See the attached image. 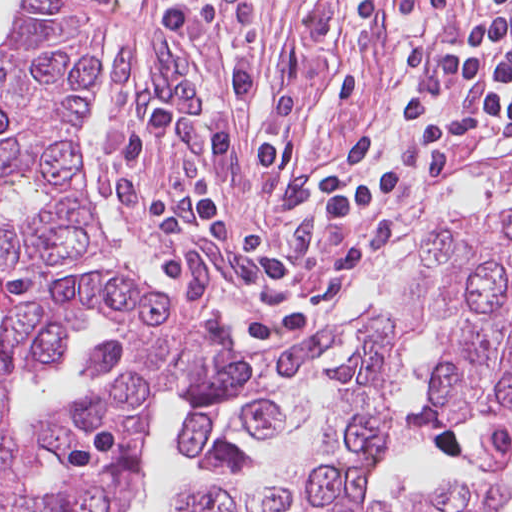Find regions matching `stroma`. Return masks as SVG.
Listing matches in <instances>:
<instances>
[{
    "mask_svg": "<svg viewBox=\"0 0 512 512\" xmlns=\"http://www.w3.org/2000/svg\"><path fill=\"white\" fill-rule=\"evenodd\" d=\"M187 1H126L87 104V176L107 170L105 152L156 110L173 104L195 126L217 118L229 96L226 59L236 45L268 91L293 110L382 81L444 36L512 10V0H195L212 12L205 42L210 86L155 22ZM23 42L24 0H16L0 54Z\"/></svg>",
    "mask_w": 512,
    "mask_h": 512,
    "instance_id": "1",
    "label": "stroma"
}]
</instances>
